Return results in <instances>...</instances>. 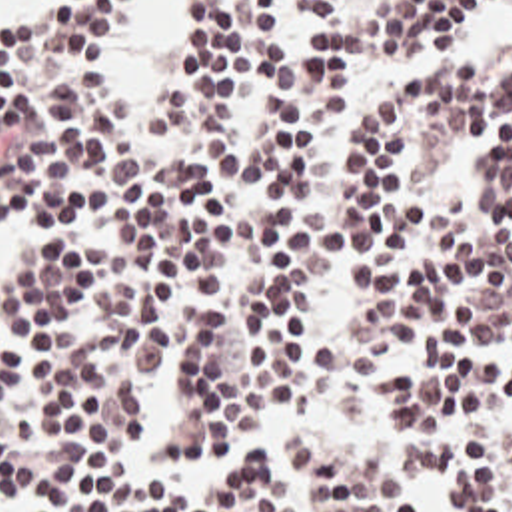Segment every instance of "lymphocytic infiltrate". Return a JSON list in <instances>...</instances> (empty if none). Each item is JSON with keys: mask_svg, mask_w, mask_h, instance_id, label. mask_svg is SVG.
<instances>
[{"mask_svg": "<svg viewBox=\"0 0 512 512\" xmlns=\"http://www.w3.org/2000/svg\"><path fill=\"white\" fill-rule=\"evenodd\" d=\"M123 0L0 19V512H273L251 407L329 512H512V0H191L129 103ZM287 512V506H285Z\"/></svg>", "mask_w": 512, "mask_h": 512, "instance_id": "1", "label": "lymphocytic infiltrate"}]
</instances>
